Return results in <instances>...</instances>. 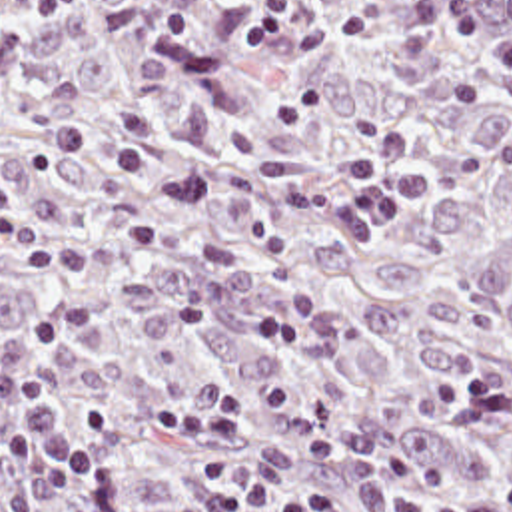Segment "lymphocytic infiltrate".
I'll return each mask as SVG.
<instances>
[{"mask_svg": "<svg viewBox=\"0 0 512 512\" xmlns=\"http://www.w3.org/2000/svg\"><path fill=\"white\" fill-rule=\"evenodd\" d=\"M20 45H26L22 29L0 17V47ZM409 149L407 129L389 127L373 143L343 157L347 181L329 211L333 237L359 241L421 197L423 177L405 185L387 177ZM68 257L56 235L0 215L2 267H54ZM98 329L102 315L94 307H74L36 315L22 339L0 337V402L10 416V430L0 446V512H52L84 480L116 472L124 462L120 412L100 402L68 418L58 390L42 380V364L54 345ZM157 412L165 430L205 444L209 500L217 512H341V496L333 486L283 488L257 472L227 464V442L247 426V408L233 390H211L193 404L163 406ZM445 512H512V488L483 504Z\"/></svg>", "mask_w": 512, "mask_h": 512, "instance_id": "obj_1", "label": "lymphocytic infiltrate"}]
</instances>
